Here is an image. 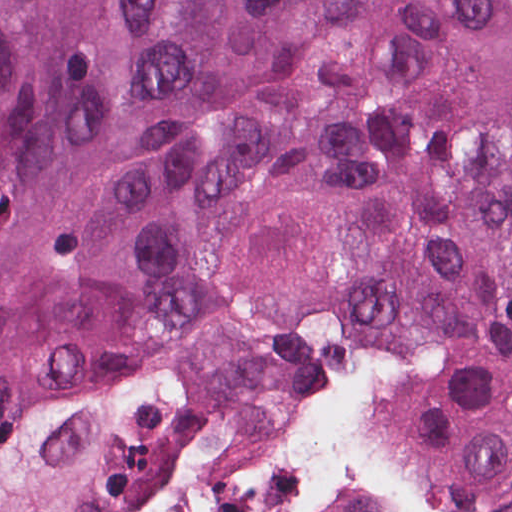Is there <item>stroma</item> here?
Instances as JSON below:
<instances>
[{"label": "stroma", "instance_id": "35a3bbf8", "mask_svg": "<svg viewBox=\"0 0 512 512\" xmlns=\"http://www.w3.org/2000/svg\"><path fill=\"white\" fill-rule=\"evenodd\" d=\"M397 362L406 381L389 414L395 431L415 466L444 487L465 512H512V500L477 475L452 469L431 456V433L448 393L446 336L403 333L386 337L328 341L296 388L283 399V424L291 449L306 465L305 405L314 389L331 378ZM240 418L180 450L118 512L133 497L152 489L188 465L207 443ZM317 478L337 498L365 512H381L383 508L384 486L369 477Z\"/></svg>", "mask_w": 512, "mask_h": 512}]
</instances>
